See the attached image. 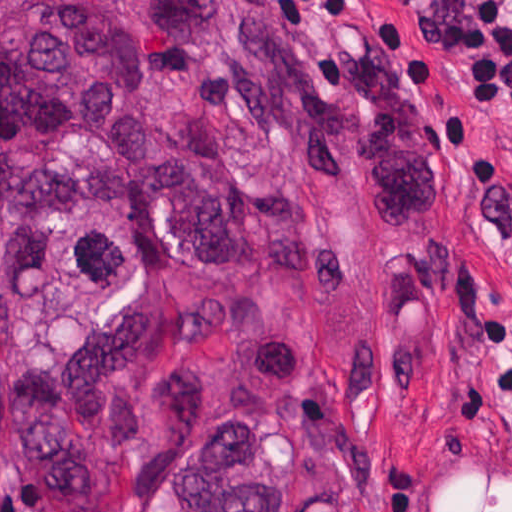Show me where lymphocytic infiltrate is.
I'll return each instance as SVG.
<instances>
[{
    "label": "lymphocytic infiltrate",
    "instance_id": "f902f5d3",
    "mask_svg": "<svg viewBox=\"0 0 512 512\" xmlns=\"http://www.w3.org/2000/svg\"><path fill=\"white\" fill-rule=\"evenodd\" d=\"M454 2L460 15L444 27L465 48L467 95L512 127V0Z\"/></svg>",
    "mask_w": 512,
    "mask_h": 512
}]
</instances>
